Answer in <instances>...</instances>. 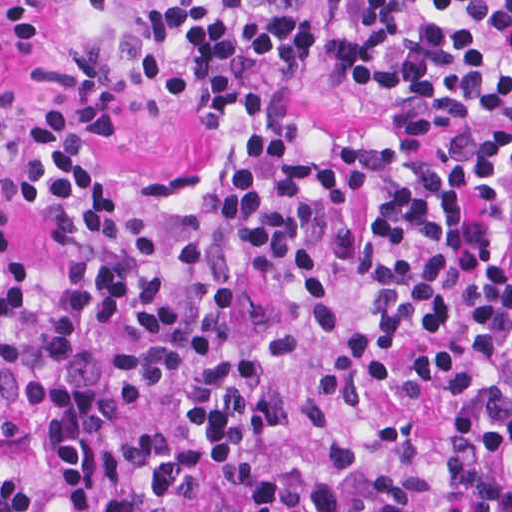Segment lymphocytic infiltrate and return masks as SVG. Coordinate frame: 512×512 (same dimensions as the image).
Masks as SVG:
<instances>
[{"mask_svg": "<svg viewBox=\"0 0 512 512\" xmlns=\"http://www.w3.org/2000/svg\"><path fill=\"white\" fill-rule=\"evenodd\" d=\"M16 42L62 41L40 74L103 132L163 109L215 127L271 113L317 65L311 0H0ZM334 72L391 88L383 135L274 117L179 255L193 278L187 441L116 435L77 370L99 329L129 338L110 376L147 409L176 369L167 261L119 209L82 127L29 120L22 196L66 259L46 326L23 267L0 306V512H136L132 465L162 458L168 501L212 483L223 512H512V269L497 236L512 194V0H348ZM12 143L0 65V155Z\"/></svg>", "mask_w": 512, "mask_h": 512, "instance_id": "obj_1", "label": "lymphocytic infiltrate"}]
</instances>
